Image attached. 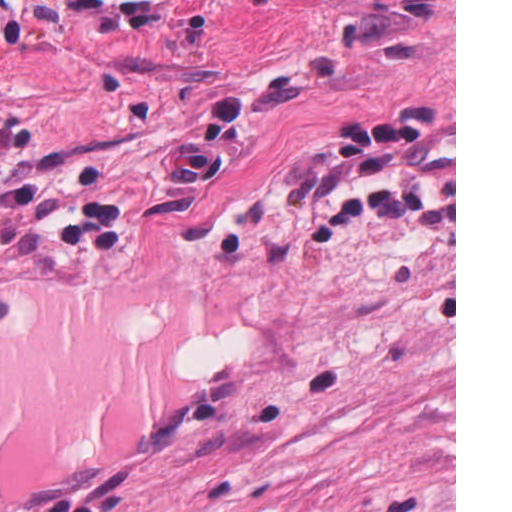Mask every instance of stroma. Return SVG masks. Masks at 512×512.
I'll list each match as a JSON object with an SVG mask.
<instances>
[{
	"label": "stroma",
	"instance_id": "35a3bbf8",
	"mask_svg": "<svg viewBox=\"0 0 512 512\" xmlns=\"http://www.w3.org/2000/svg\"><path fill=\"white\" fill-rule=\"evenodd\" d=\"M270 0H0V156Z\"/></svg>",
	"mask_w": 512,
	"mask_h": 512
}]
</instances>
